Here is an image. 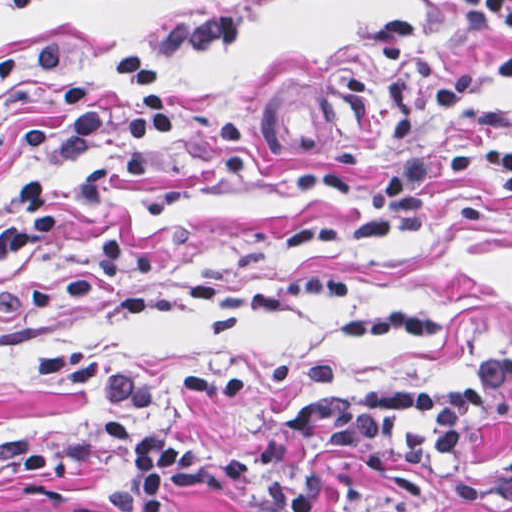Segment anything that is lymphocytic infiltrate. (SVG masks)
<instances>
[{
	"instance_id": "1",
	"label": "lymphocytic infiltrate",
	"mask_w": 512,
	"mask_h": 512,
	"mask_svg": "<svg viewBox=\"0 0 512 512\" xmlns=\"http://www.w3.org/2000/svg\"><path fill=\"white\" fill-rule=\"evenodd\" d=\"M56 1L7 0L6 5L12 13H27ZM453 6L465 19L512 29V0H454ZM247 26L248 18L237 12L161 21L141 34L120 63L115 77L123 102L108 110L90 98L62 44L42 42L34 70L56 91L59 109L36 121L24 137V180L0 192V243L28 245L54 227L62 204L55 161L84 144L111 140L119 168L134 179L157 170L181 121L144 54L228 45ZM490 170L512 185V144L420 142L392 159L368 192H359L338 171L310 174L296 183L303 193L355 204L361 211L352 220H298L289 244L348 246L401 230L424 218L433 181ZM511 404L512 356H503L459 383L305 400L262 449L219 451L173 431H138L110 420L98 432L125 451L128 463L103 492V506L111 512H162L173 497L206 495L250 512H317L325 485L295 461L294 446H312L367 473L399 470L428 477L444 471L471 439L493 429ZM447 502L458 512L511 510L512 463L474 473L447 490Z\"/></svg>"
}]
</instances>
